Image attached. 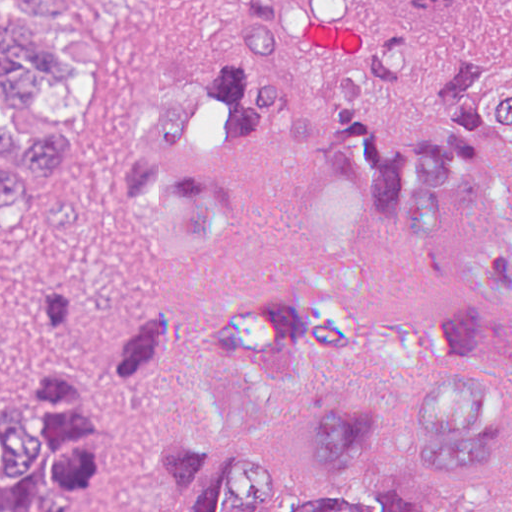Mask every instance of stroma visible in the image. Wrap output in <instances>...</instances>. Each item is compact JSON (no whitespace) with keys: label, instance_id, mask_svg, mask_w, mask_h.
<instances>
[{"label":"stroma","instance_id":"1","mask_svg":"<svg viewBox=\"0 0 512 512\" xmlns=\"http://www.w3.org/2000/svg\"><path fill=\"white\" fill-rule=\"evenodd\" d=\"M220 0H0L55 57L54 90L15 113L25 139L67 143L58 174L26 201L0 205V403L25 367L30 278H61L77 304V360L103 362L120 335L154 312L181 331L158 374L118 398L93 512H129L159 490L173 435L204 419L198 369L215 317L237 297L282 292L313 264L311 178L282 145L234 179L238 225L203 250L181 279L153 267L127 204L122 148L135 110L211 66ZM512 12V0H491ZM355 480L405 483L454 512L512 495V460L490 470H435L415 454L397 416L379 427L373 460Z\"/></svg>","mask_w":512,"mask_h":512}]
</instances>
